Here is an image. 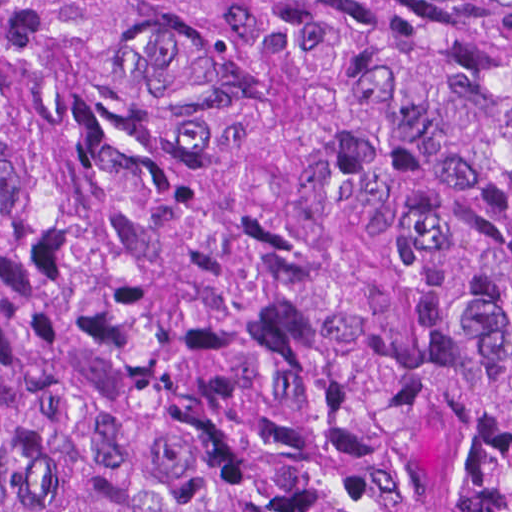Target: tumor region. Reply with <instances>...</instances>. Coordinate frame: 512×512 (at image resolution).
I'll list each match as a JSON object with an SVG mask.
<instances>
[{"label":"tumor region","instance_id":"tumor-region-1","mask_svg":"<svg viewBox=\"0 0 512 512\" xmlns=\"http://www.w3.org/2000/svg\"><path fill=\"white\" fill-rule=\"evenodd\" d=\"M0 512H512V0H0Z\"/></svg>","mask_w":512,"mask_h":512}]
</instances>
